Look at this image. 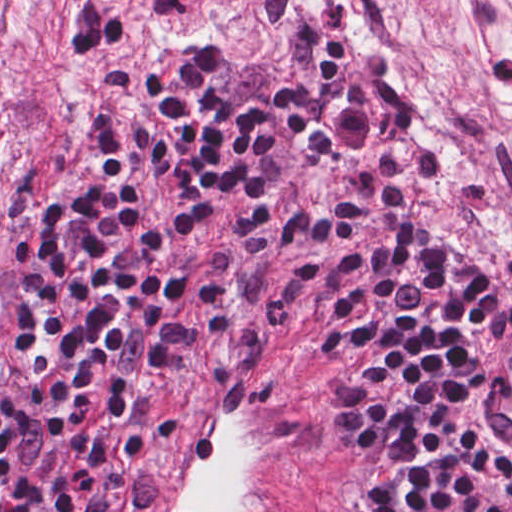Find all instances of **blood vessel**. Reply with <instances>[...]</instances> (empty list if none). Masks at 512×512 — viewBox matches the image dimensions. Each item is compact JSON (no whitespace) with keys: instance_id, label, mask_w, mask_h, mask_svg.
<instances>
[{"instance_id":"blood-vessel-1","label":"blood vessel","mask_w":512,"mask_h":512,"mask_svg":"<svg viewBox=\"0 0 512 512\" xmlns=\"http://www.w3.org/2000/svg\"><path fill=\"white\" fill-rule=\"evenodd\" d=\"M138 1L171 35L211 34L242 2ZM507 345L478 389L474 420L512 449ZM194 369L117 456L105 512H345L332 449L273 361L245 343L190 378Z\"/></svg>"}]
</instances>
